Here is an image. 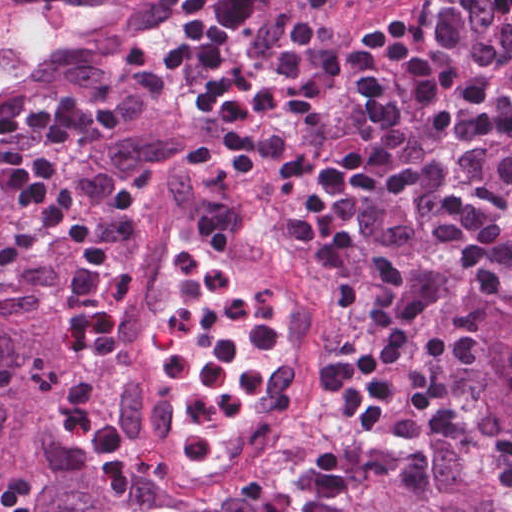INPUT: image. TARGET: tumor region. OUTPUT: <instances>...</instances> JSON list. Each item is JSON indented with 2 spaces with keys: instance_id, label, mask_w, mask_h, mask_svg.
<instances>
[{
  "instance_id": "tumor-region-1",
  "label": "tumor region",
  "mask_w": 512,
  "mask_h": 512,
  "mask_svg": "<svg viewBox=\"0 0 512 512\" xmlns=\"http://www.w3.org/2000/svg\"><path fill=\"white\" fill-rule=\"evenodd\" d=\"M471 2L451 21L463 22ZM457 61L490 67L485 77L512 100V17L469 39ZM65 76L87 88H101L107 69L86 62ZM430 142L419 97L408 84L397 122L377 159L399 165L420 156ZM183 150L184 141L176 137L122 135L106 144L102 154L113 169H132ZM499 155L500 147L475 135L466 117L439 174L512 225V195L496 174ZM171 192L200 202L184 164L168 170ZM436 205L432 195L416 192L376 205L362 228L358 263L338 270L325 261L303 280L390 285L417 313L421 328L460 303L478 305L486 313L482 347L470 365L453 374L469 439H429L427 498L385 475L367 485L348 512H512V276L500 293L478 291L428 238ZM83 352L67 338L65 324L0 310V485L25 493L34 512H114L69 472L84 468L86 458L47 419L50 411L34 391L36 376L48 362L60 356L75 364Z\"/></svg>"
}]
</instances>
